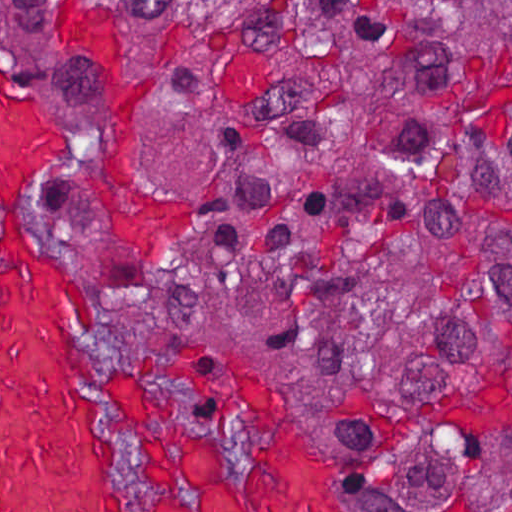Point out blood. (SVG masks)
Listing matches in <instances>:
<instances>
[{
	"mask_svg": "<svg viewBox=\"0 0 512 512\" xmlns=\"http://www.w3.org/2000/svg\"><path fill=\"white\" fill-rule=\"evenodd\" d=\"M60 165L118 225L165 238L171 218L116 189L69 130L0 65V512H350L335 477L261 371L240 374L236 409L253 445L237 477L213 426L171 429L134 381L115 378L150 468L136 504L109 439L79 311L100 302L40 234Z\"/></svg>",
	"mask_w": 512,
	"mask_h": 512,
	"instance_id": "1",
	"label": "blood"
}]
</instances>
